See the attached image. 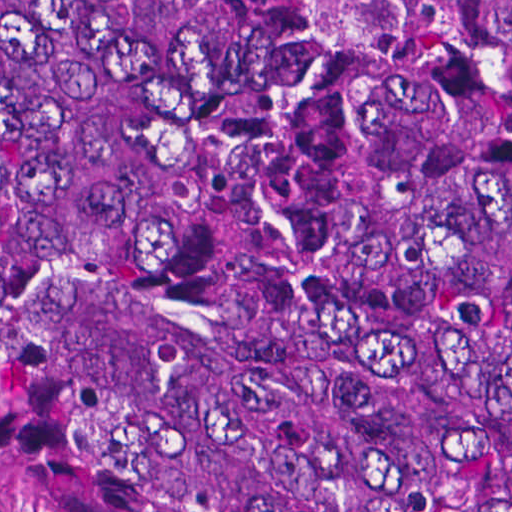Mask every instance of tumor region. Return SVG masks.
Returning <instances> with one entry per match:
<instances>
[{"mask_svg":"<svg viewBox=\"0 0 512 512\" xmlns=\"http://www.w3.org/2000/svg\"><path fill=\"white\" fill-rule=\"evenodd\" d=\"M0 494L512 512V0H0Z\"/></svg>","mask_w":512,"mask_h":512,"instance_id":"tumor-region-1","label":"tumor region"}]
</instances>
